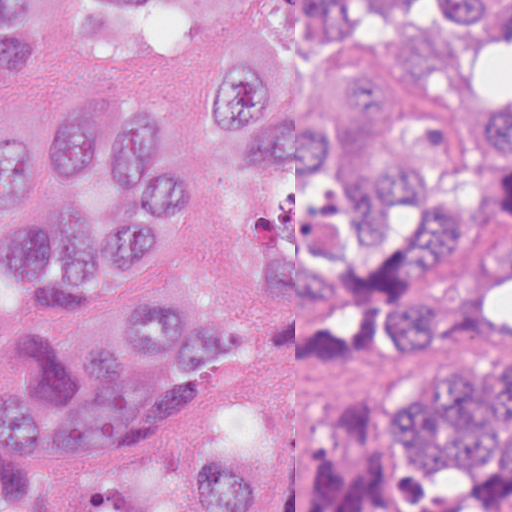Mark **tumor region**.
I'll return each mask as SVG.
<instances>
[{"label":"tumor region","mask_w":512,"mask_h":512,"mask_svg":"<svg viewBox=\"0 0 512 512\" xmlns=\"http://www.w3.org/2000/svg\"><path fill=\"white\" fill-rule=\"evenodd\" d=\"M48 0H0V70ZM82 43L138 65L201 56L197 117L229 143L271 324L347 360L446 335L512 338V93L463 97L443 60L512 39V0H79ZM190 141L149 84H83L0 137V450L125 456L242 364L254 321L177 208ZM256 449L77 512H245ZM287 512H512V353L409 368L367 419L312 432ZM0 512H75L0 452Z\"/></svg>","instance_id":"tumor-region-1"}]
</instances>
